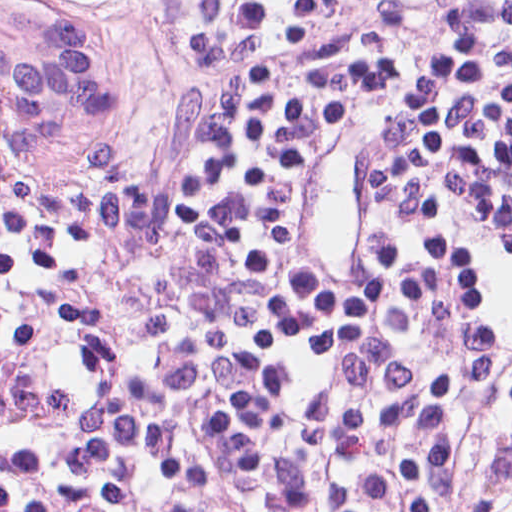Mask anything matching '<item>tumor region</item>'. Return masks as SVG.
Wrapping results in <instances>:
<instances>
[{
  "mask_svg": "<svg viewBox=\"0 0 512 512\" xmlns=\"http://www.w3.org/2000/svg\"><path fill=\"white\" fill-rule=\"evenodd\" d=\"M98 1L0 0V147L73 188L113 162L147 90V60L105 27Z\"/></svg>",
  "mask_w": 512,
  "mask_h": 512,
  "instance_id": "e687c5a6",
  "label": "tumor region"
}]
</instances>
